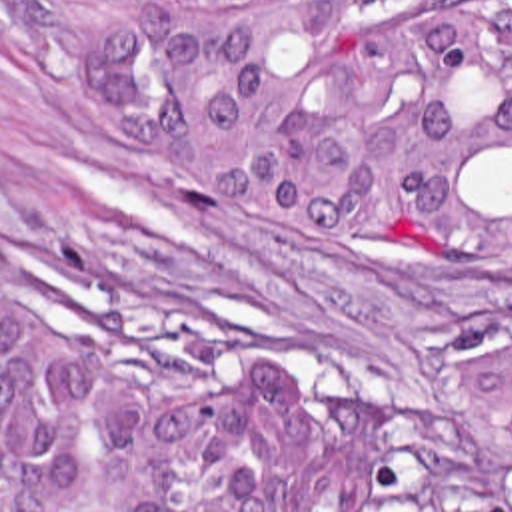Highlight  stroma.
I'll return each instance as SVG.
<instances>
[{"mask_svg":"<svg viewBox=\"0 0 512 512\" xmlns=\"http://www.w3.org/2000/svg\"><path fill=\"white\" fill-rule=\"evenodd\" d=\"M0 265L86 305L114 343L198 382L282 357L318 408L392 412L430 512L440 382L512 345V253L432 233H346L204 203L136 123L0 0Z\"/></svg>","mask_w":512,"mask_h":512,"instance_id":"1","label":"stroma"}]
</instances>
